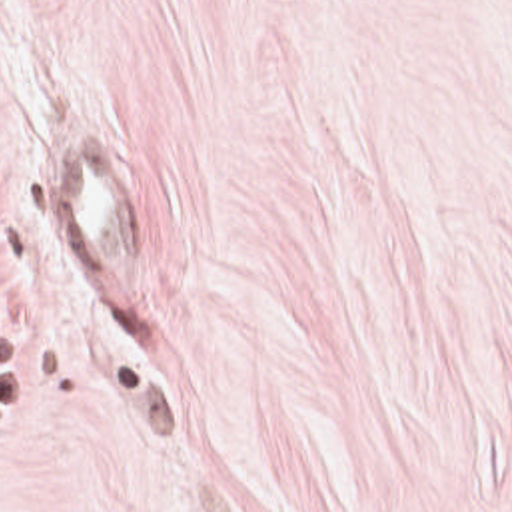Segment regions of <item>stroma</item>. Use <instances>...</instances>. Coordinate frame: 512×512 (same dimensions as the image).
<instances>
[{
    "instance_id": "1",
    "label": "stroma",
    "mask_w": 512,
    "mask_h": 512,
    "mask_svg": "<svg viewBox=\"0 0 512 512\" xmlns=\"http://www.w3.org/2000/svg\"><path fill=\"white\" fill-rule=\"evenodd\" d=\"M0 512H512V0H0Z\"/></svg>"
}]
</instances>
